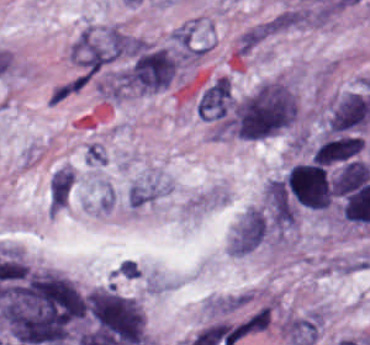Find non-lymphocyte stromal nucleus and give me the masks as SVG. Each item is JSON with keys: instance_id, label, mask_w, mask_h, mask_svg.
Listing matches in <instances>:
<instances>
[{"instance_id": "1", "label": "non-lymphocyte stromal nucleus", "mask_w": 370, "mask_h": 345, "mask_svg": "<svg viewBox=\"0 0 370 345\" xmlns=\"http://www.w3.org/2000/svg\"><path fill=\"white\" fill-rule=\"evenodd\" d=\"M295 109V97L286 82L264 79L235 102L219 134L260 138L286 127Z\"/></svg>"}, {"instance_id": "2", "label": "non-lymphocyte stromal nucleus", "mask_w": 370, "mask_h": 345, "mask_svg": "<svg viewBox=\"0 0 370 345\" xmlns=\"http://www.w3.org/2000/svg\"><path fill=\"white\" fill-rule=\"evenodd\" d=\"M322 321V313L318 310L291 314L280 320V332L293 345H314L319 337Z\"/></svg>"}, {"instance_id": "3", "label": "non-lymphocyte stromal nucleus", "mask_w": 370, "mask_h": 345, "mask_svg": "<svg viewBox=\"0 0 370 345\" xmlns=\"http://www.w3.org/2000/svg\"><path fill=\"white\" fill-rule=\"evenodd\" d=\"M283 31V15L270 16L240 30L236 35L234 51L238 56L244 57Z\"/></svg>"}, {"instance_id": "4", "label": "non-lymphocyte stromal nucleus", "mask_w": 370, "mask_h": 345, "mask_svg": "<svg viewBox=\"0 0 370 345\" xmlns=\"http://www.w3.org/2000/svg\"><path fill=\"white\" fill-rule=\"evenodd\" d=\"M232 103L229 79L217 77L199 96L195 110L203 119L225 115Z\"/></svg>"}]
</instances>
